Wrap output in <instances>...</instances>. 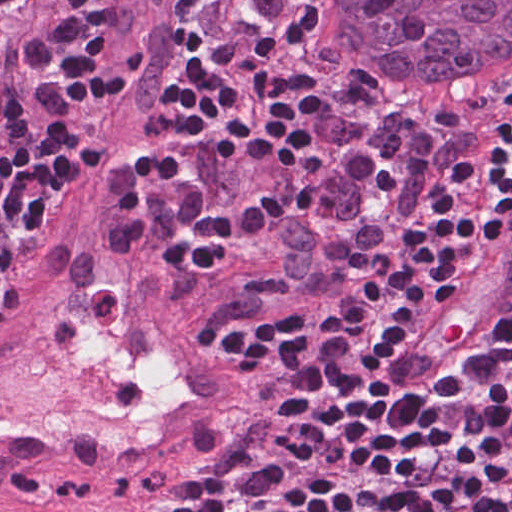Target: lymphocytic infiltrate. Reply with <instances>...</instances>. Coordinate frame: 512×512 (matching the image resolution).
I'll return each mask as SVG.
<instances>
[{
    "mask_svg": "<svg viewBox=\"0 0 512 512\" xmlns=\"http://www.w3.org/2000/svg\"><path fill=\"white\" fill-rule=\"evenodd\" d=\"M105 1L0 0V295L35 221L83 168L119 76L90 35ZM310 44L298 0H194V62L176 95L252 180L210 200L192 164L154 149L146 169L173 221L170 288L211 287L299 209L292 88ZM379 129H395L408 264L335 317L272 333L217 327L266 386V436L169 512H512V309L427 406L393 398L381 369L512 225V109L457 117L429 105L324 141Z\"/></svg>",
    "mask_w": 512,
    "mask_h": 512,
    "instance_id": "f902f5d3",
    "label": "lymphocytic infiltrate"
}]
</instances>
